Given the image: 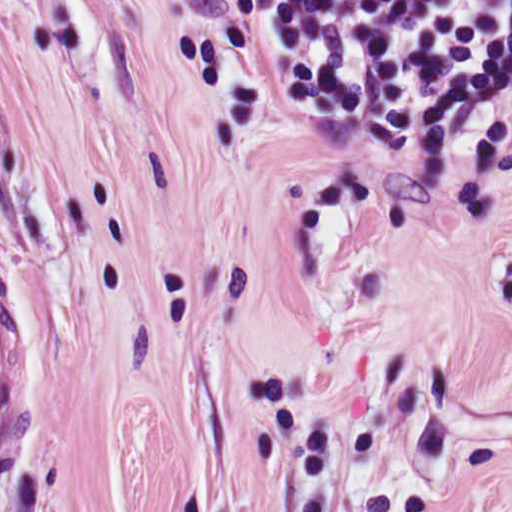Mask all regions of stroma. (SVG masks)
I'll return each mask as SVG.
<instances>
[{
    "instance_id": "obj_1",
    "label": "stroma",
    "mask_w": 512,
    "mask_h": 512,
    "mask_svg": "<svg viewBox=\"0 0 512 512\" xmlns=\"http://www.w3.org/2000/svg\"><path fill=\"white\" fill-rule=\"evenodd\" d=\"M0 512H55L512 309V75L432 131L276 91L226 0H0Z\"/></svg>"
}]
</instances>
